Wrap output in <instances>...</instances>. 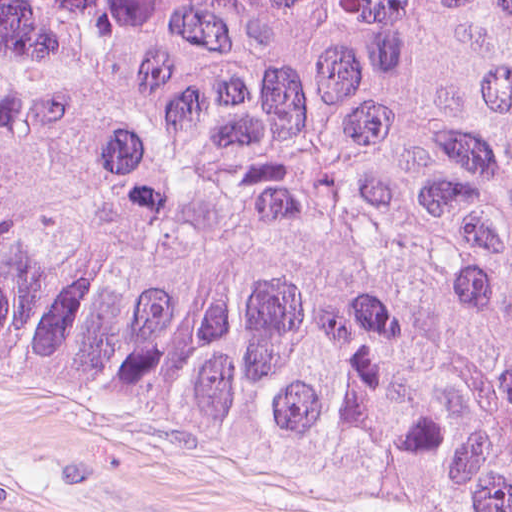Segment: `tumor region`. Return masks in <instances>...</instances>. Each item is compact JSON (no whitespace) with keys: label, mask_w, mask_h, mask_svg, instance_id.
I'll return each instance as SVG.
<instances>
[{"label":"tumor region","mask_w":512,"mask_h":512,"mask_svg":"<svg viewBox=\"0 0 512 512\" xmlns=\"http://www.w3.org/2000/svg\"><path fill=\"white\" fill-rule=\"evenodd\" d=\"M0 363L512 512V0H0Z\"/></svg>","instance_id":"obj_1"}]
</instances>
